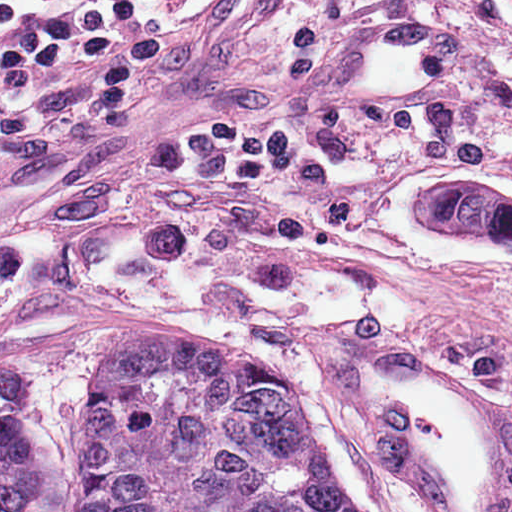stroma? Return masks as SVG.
<instances>
[{
	"label": "stroma",
	"instance_id": "1",
	"mask_svg": "<svg viewBox=\"0 0 512 512\" xmlns=\"http://www.w3.org/2000/svg\"><path fill=\"white\" fill-rule=\"evenodd\" d=\"M47 23L145 16L137 140L47 147L0 131V364L35 379L24 512H85L93 411L130 337L293 388L328 470L373 512L405 483L313 383L322 331L452 348L512 386V316L474 232L418 192L448 176L410 104H311L323 38L370 0H5Z\"/></svg>",
	"mask_w": 512,
	"mask_h": 512
}]
</instances>
